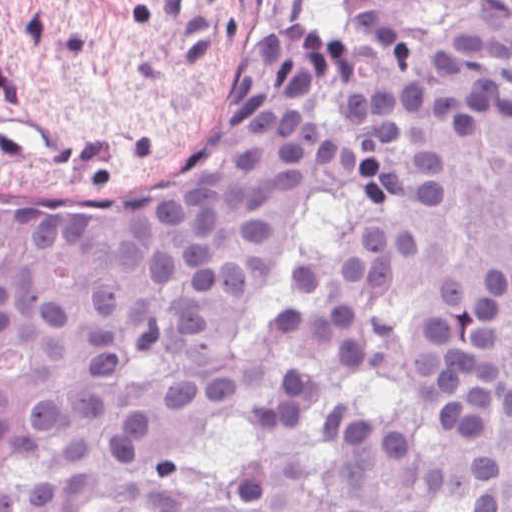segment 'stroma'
<instances>
[{
	"instance_id": "1",
	"label": "stroma",
	"mask_w": 512,
	"mask_h": 512,
	"mask_svg": "<svg viewBox=\"0 0 512 512\" xmlns=\"http://www.w3.org/2000/svg\"><path fill=\"white\" fill-rule=\"evenodd\" d=\"M356 0H0V192L116 199L288 30L336 37Z\"/></svg>"
}]
</instances>
